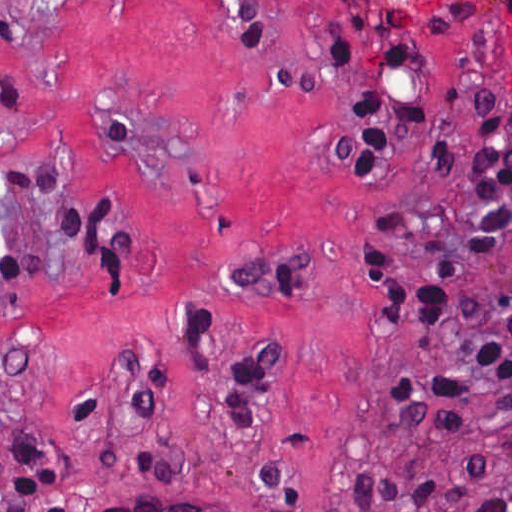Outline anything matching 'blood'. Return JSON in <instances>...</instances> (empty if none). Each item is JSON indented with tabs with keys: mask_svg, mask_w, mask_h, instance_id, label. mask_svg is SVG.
Listing matches in <instances>:
<instances>
[{
	"mask_svg": "<svg viewBox=\"0 0 512 512\" xmlns=\"http://www.w3.org/2000/svg\"><path fill=\"white\" fill-rule=\"evenodd\" d=\"M496 12L512 21V0H489Z\"/></svg>",
	"mask_w": 512,
	"mask_h": 512,
	"instance_id": "1",
	"label": "blood"
}]
</instances>
